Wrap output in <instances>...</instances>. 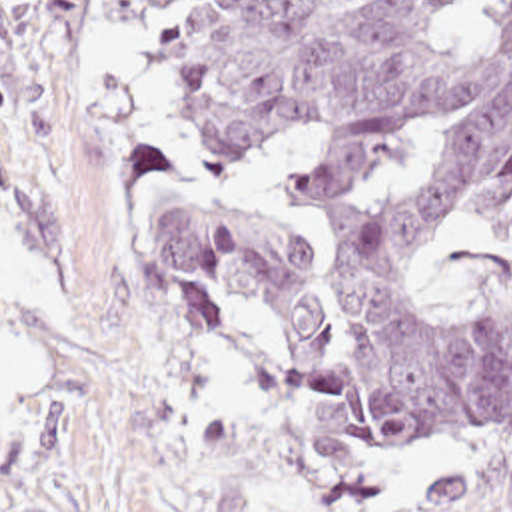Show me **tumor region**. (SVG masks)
I'll use <instances>...</instances> for the list:
<instances>
[{"instance_id": "obj_1", "label": "tumor region", "mask_w": 512, "mask_h": 512, "mask_svg": "<svg viewBox=\"0 0 512 512\" xmlns=\"http://www.w3.org/2000/svg\"><path fill=\"white\" fill-rule=\"evenodd\" d=\"M160 104L204 152L310 144L286 200L328 266L210 210L160 222L164 286L274 344L314 402L375 447L512 439V296L445 302L435 230H512V0H154ZM421 512H512V471L427 481Z\"/></svg>"}]
</instances>
